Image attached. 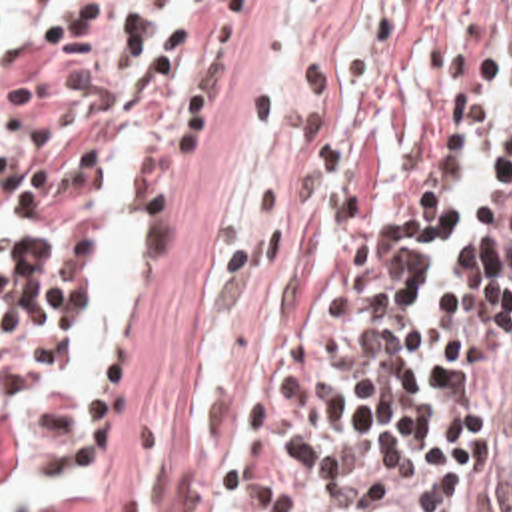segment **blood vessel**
Segmentation results:
<instances>
[{
    "label": "blood vessel",
    "mask_w": 512,
    "mask_h": 512,
    "mask_svg": "<svg viewBox=\"0 0 512 512\" xmlns=\"http://www.w3.org/2000/svg\"><path fill=\"white\" fill-rule=\"evenodd\" d=\"M397 477L365 491L347 512H439V475L425 467L383 471Z\"/></svg>",
    "instance_id": "8fb6f2fc"
}]
</instances>
